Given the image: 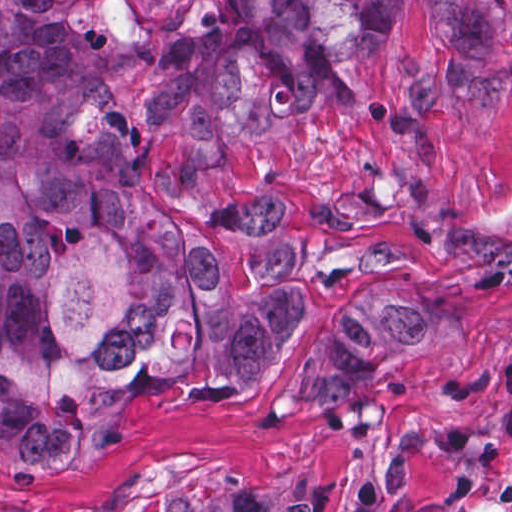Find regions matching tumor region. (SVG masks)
I'll list each match as a JSON object with an SVG mask.
<instances>
[{"label":"tumor region","instance_id":"obj_1","mask_svg":"<svg viewBox=\"0 0 512 512\" xmlns=\"http://www.w3.org/2000/svg\"><path fill=\"white\" fill-rule=\"evenodd\" d=\"M410 1L209 0L159 88L195 132L310 121L342 102ZM439 1L452 47L492 49L494 0ZM104 54L100 0H0V466L20 473L98 459L133 438L144 402L257 389L296 321L261 248L226 258L212 230L140 207ZM441 345L421 295L381 286L324 334L289 406L333 404ZM286 505L277 488L165 512Z\"/></svg>","mask_w":512,"mask_h":512}]
</instances>
